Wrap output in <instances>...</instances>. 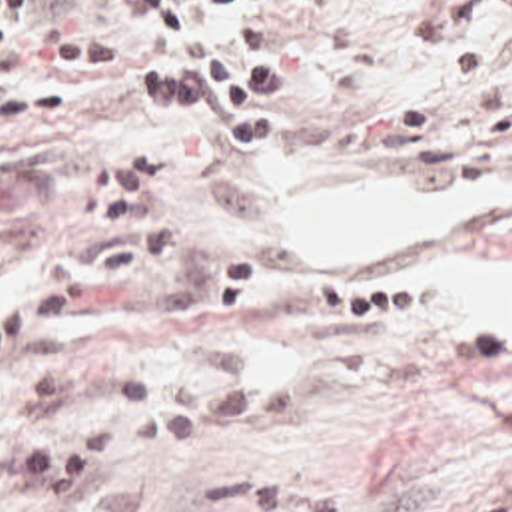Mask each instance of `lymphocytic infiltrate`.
I'll use <instances>...</instances> for the list:
<instances>
[{
  "label": "lymphocytic infiltrate",
  "instance_id": "obj_1",
  "mask_svg": "<svg viewBox=\"0 0 512 512\" xmlns=\"http://www.w3.org/2000/svg\"><path fill=\"white\" fill-rule=\"evenodd\" d=\"M145 26L137 34H65L45 48L55 68L95 72L143 58H173L135 68L131 98L151 116L215 122L225 148H261L275 140V96L289 92V60L275 50L267 26L231 30L199 12L229 0H129ZM33 0H0V60L17 54L19 24Z\"/></svg>",
  "mask_w": 512,
  "mask_h": 512
}]
</instances>
